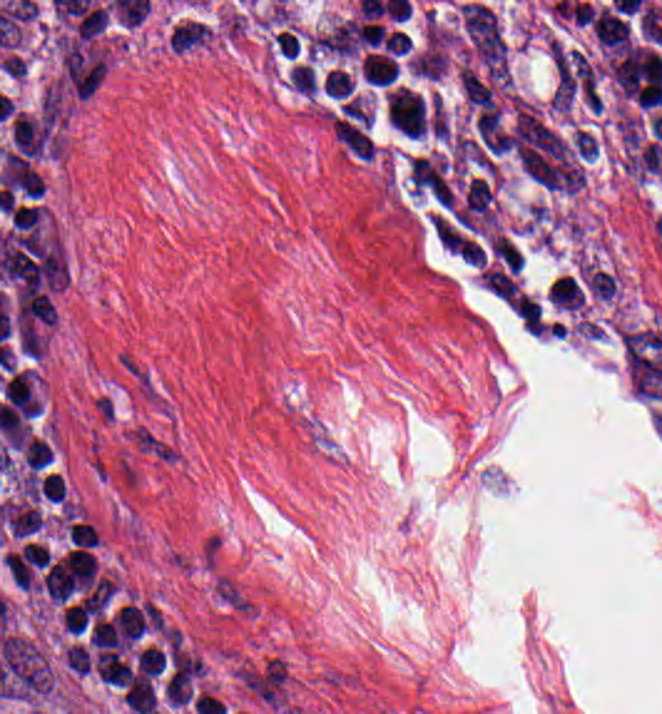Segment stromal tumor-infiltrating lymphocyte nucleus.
Here are the masks:
<instances>
[{"label":"stromal tumor-infiltrating lymphocyte nucleus","mask_w":662,"mask_h":714,"mask_svg":"<svg viewBox=\"0 0 662 714\" xmlns=\"http://www.w3.org/2000/svg\"><path fill=\"white\" fill-rule=\"evenodd\" d=\"M546 53L554 105L597 110L600 94L587 56L550 39Z\"/></svg>","instance_id":"obj_1"}]
</instances>
